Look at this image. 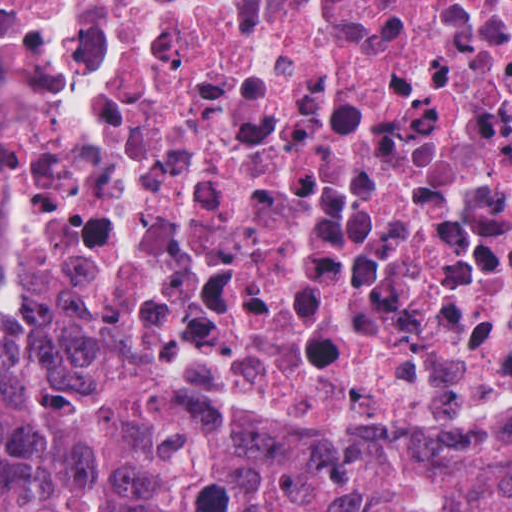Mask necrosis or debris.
<instances>
[{
	"label": "necrosis or debris",
	"mask_w": 512,
	"mask_h": 512,
	"mask_svg": "<svg viewBox=\"0 0 512 512\" xmlns=\"http://www.w3.org/2000/svg\"><path fill=\"white\" fill-rule=\"evenodd\" d=\"M0 204L234 420L512 433V0H0Z\"/></svg>",
	"instance_id": "4bbe7bcc"
}]
</instances>
